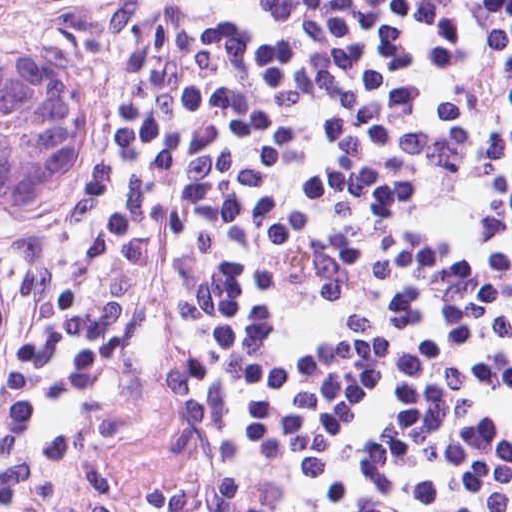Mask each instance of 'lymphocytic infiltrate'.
<instances>
[{
	"instance_id": "1",
	"label": "lymphocytic infiltrate",
	"mask_w": 512,
	"mask_h": 512,
	"mask_svg": "<svg viewBox=\"0 0 512 512\" xmlns=\"http://www.w3.org/2000/svg\"><path fill=\"white\" fill-rule=\"evenodd\" d=\"M113 96L0 229V512H512V0H0Z\"/></svg>"
}]
</instances>
